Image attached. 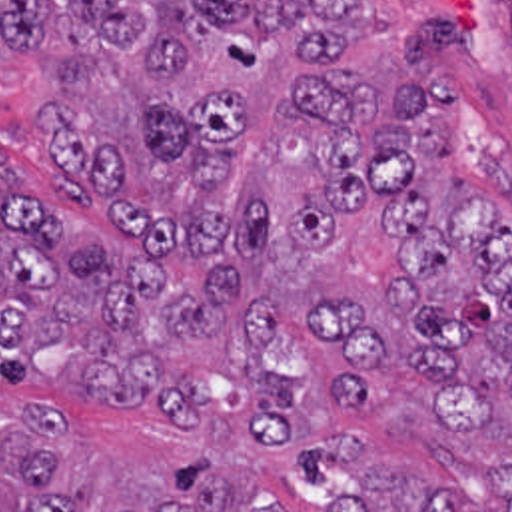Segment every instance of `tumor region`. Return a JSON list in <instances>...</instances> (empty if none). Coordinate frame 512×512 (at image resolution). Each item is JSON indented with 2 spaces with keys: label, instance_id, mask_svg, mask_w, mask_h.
<instances>
[{
  "label": "tumor region",
  "instance_id": "e687c5a6",
  "mask_svg": "<svg viewBox=\"0 0 512 512\" xmlns=\"http://www.w3.org/2000/svg\"><path fill=\"white\" fill-rule=\"evenodd\" d=\"M0 45L35 47L47 75L31 115L49 185L123 227L147 259L233 253L297 275L299 245L366 211L392 237L384 338L366 298H311V326L343 360L331 392L370 404L382 366H406L456 428L512 402V231L456 175L448 123L458 89L436 77L458 47L452 11L392 25L363 0H0ZM281 316L245 300L233 269L179 285L159 267L87 245L33 203L0 157V376L37 380L61 348L81 388L153 404L191 426L199 380L247 386L253 444H299L305 376L267 362ZM65 466V430L41 402L0 414V512H97V480ZM512 512V498L508 504ZM121 512L273 508L205 458L161 476ZM323 512H472L446 488L384 466Z\"/></svg>",
  "mask_w": 512,
  "mask_h": 512
}]
</instances>
